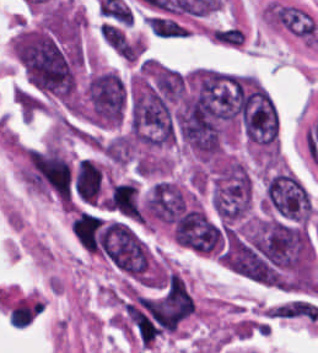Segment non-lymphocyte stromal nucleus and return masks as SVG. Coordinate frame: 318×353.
Wrapping results in <instances>:
<instances>
[{"mask_svg": "<svg viewBox=\"0 0 318 353\" xmlns=\"http://www.w3.org/2000/svg\"><path fill=\"white\" fill-rule=\"evenodd\" d=\"M101 41L125 62H136L142 55V42L117 20H104L98 24Z\"/></svg>", "mask_w": 318, "mask_h": 353, "instance_id": "non-lymphocyte-stromal-nucleus-1", "label": "non-lymphocyte stromal nucleus"}, {"mask_svg": "<svg viewBox=\"0 0 318 353\" xmlns=\"http://www.w3.org/2000/svg\"><path fill=\"white\" fill-rule=\"evenodd\" d=\"M147 25L152 35L162 37L188 36L185 26L173 19L147 15Z\"/></svg>", "mask_w": 318, "mask_h": 353, "instance_id": "non-lymphocyte-stromal-nucleus-2", "label": "non-lymphocyte stromal nucleus"}]
</instances>
